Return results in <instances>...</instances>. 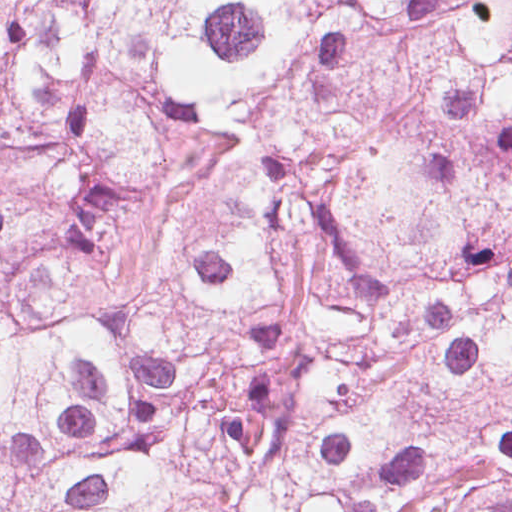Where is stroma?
Returning <instances> with one entry per match:
<instances>
[{
	"mask_svg": "<svg viewBox=\"0 0 512 512\" xmlns=\"http://www.w3.org/2000/svg\"><path fill=\"white\" fill-rule=\"evenodd\" d=\"M34 0H0V28H27Z\"/></svg>",
	"mask_w": 512,
	"mask_h": 512,
	"instance_id": "1",
	"label": "stroma"
}]
</instances>
